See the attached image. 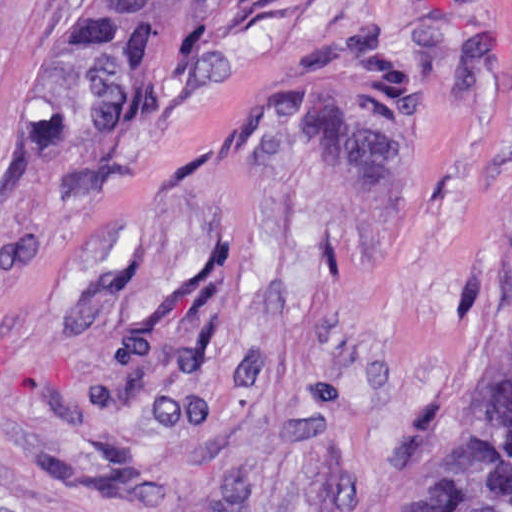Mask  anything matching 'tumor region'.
Wrapping results in <instances>:
<instances>
[{
  "label": "tumor region",
  "mask_w": 512,
  "mask_h": 512,
  "mask_svg": "<svg viewBox=\"0 0 512 512\" xmlns=\"http://www.w3.org/2000/svg\"><path fill=\"white\" fill-rule=\"evenodd\" d=\"M283 0H79L40 77L45 140L141 123L191 65ZM352 512H512V360L443 366L352 471Z\"/></svg>",
  "instance_id": "obj_1"
}]
</instances>
